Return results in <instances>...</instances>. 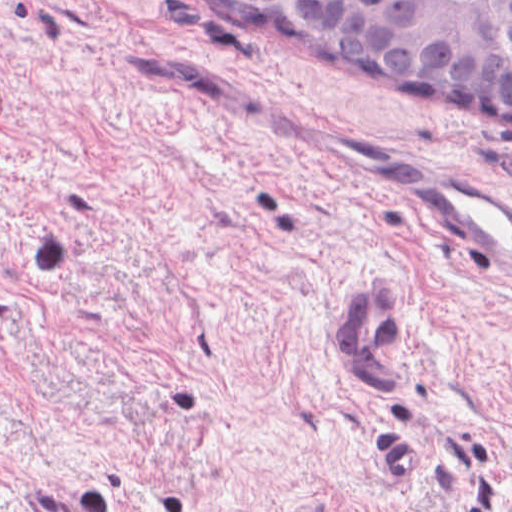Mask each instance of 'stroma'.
Segmentation results:
<instances>
[{"mask_svg":"<svg viewBox=\"0 0 512 512\" xmlns=\"http://www.w3.org/2000/svg\"><path fill=\"white\" fill-rule=\"evenodd\" d=\"M418 165L512 197V132L173 0H0V512H512V283ZM394 273L381 399L339 305Z\"/></svg>","mask_w":512,"mask_h":512,"instance_id":"35a3bbf8","label":"stroma"}]
</instances>
